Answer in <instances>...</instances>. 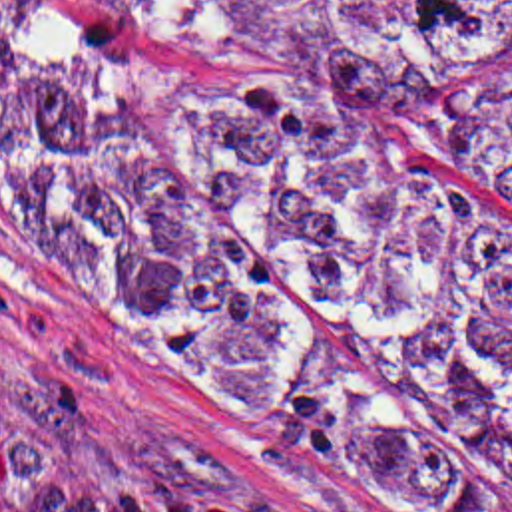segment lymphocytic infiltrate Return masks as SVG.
<instances>
[{"instance_id":"1","label":"lymphocytic infiltrate","mask_w":512,"mask_h":512,"mask_svg":"<svg viewBox=\"0 0 512 512\" xmlns=\"http://www.w3.org/2000/svg\"><path fill=\"white\" fill-rule=\"evenodd\" d=\"M0 512H265L233 495L80 457L0 395Z\"/></svg>"}]
</instances>
